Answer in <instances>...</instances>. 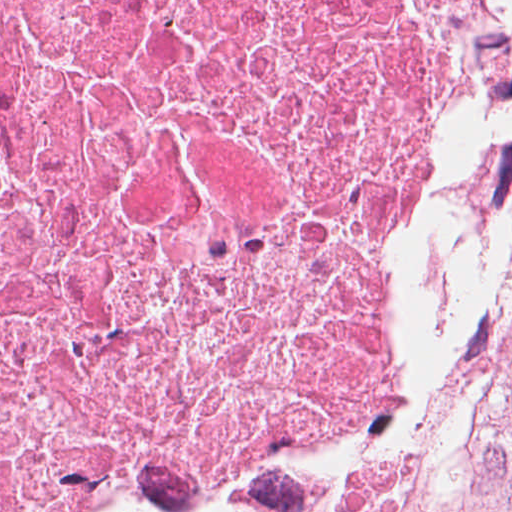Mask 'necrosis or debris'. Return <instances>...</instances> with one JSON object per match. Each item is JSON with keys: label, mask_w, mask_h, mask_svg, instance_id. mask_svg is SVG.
<instances>
[{"label": "necrosis or debris", "mask_w": 512, "mask_h": 512, "mask_svg": "<svg viewBox=\"0 0 512 512\" xmlns=\"http://www.w3.org/2000/svg\"><path fill=\"white\" fill-rule=\"evenodd\" d=\"M347 0H0V512H237Z\"/></svg>", "instance_id": "1"}]
</instances>
